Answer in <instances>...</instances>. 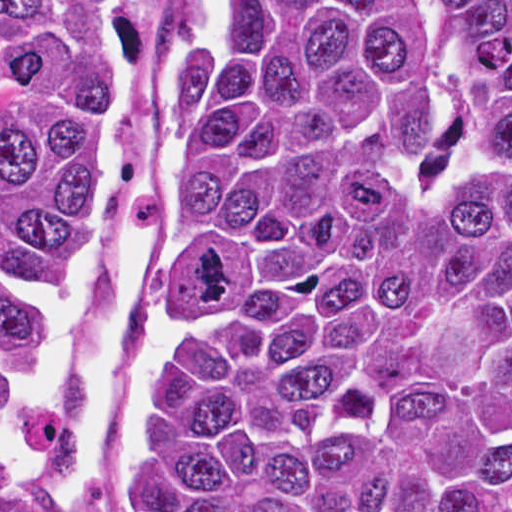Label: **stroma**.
<instances>
[{
	"instance_id": "stroma-1",
	"label": "stroma",
	"mask_w": 512,
	"mask_h": 512,
	"mask_svg": "<svg viewBox=\"0 0 512 512\" xmlns=\"http://www.w3.org/2000/svg\"><path fill=\"white\" fill-rule=\"evenodd\" d=\"M159 0H123L121 52L109 97L106 222L79 285L61 289L47 265L50 393L70 417L66 435L29 444L0 481V512H124L140 406L161 362L159 296L167 282V140L173 71L154 94ZM211 0H186L173 69Z\"/></svg>"
}]
</instances>
